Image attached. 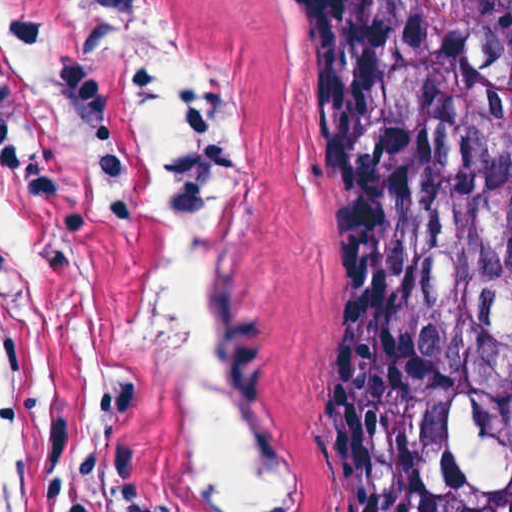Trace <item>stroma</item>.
I'll return each mask as SVG.
<instances>
[{
    "mask_svg": "<svg viewBox=\"0 0 512 512\" xmlns=\"http://www.w3.org/2000/svg\"><path fill=\"white\" fill-rule=\"evenodd\" d=\"M73 0H0V512H181L158 191L60 82ZM233 94L210 270L250 403L244 512H335L339 351L321 279V98L295 0H162Z\"/></svg>",
    "mask_w": 512,
    "mask_h": 512,
    "instance_id": "1",
    "label": "stroma"
}]
</instances>
